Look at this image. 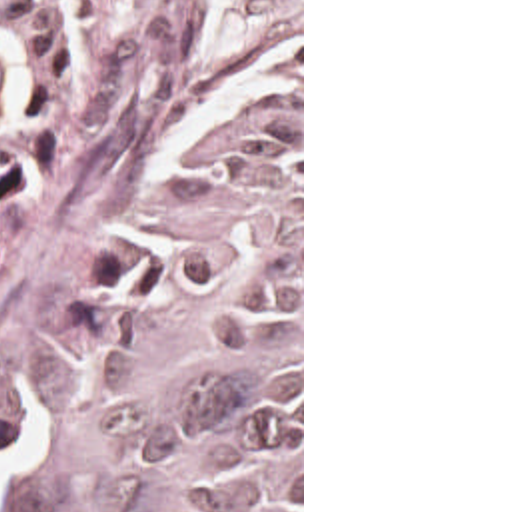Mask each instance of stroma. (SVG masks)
Here are the masks:
<instances>
[{"instance_id":"stroma-1","label":"stroma","mask_w":512,"mask_h":512,"mask_svg":"<svg viewBox=\"0 0 512 512\" xmlns=\"http://www.w3.org/2000/svg\"><path fill=\"white\" fill-rule=\"evenodd\" d=\"M300 72V512H304V0H98L64 98L0 188V512L46 395L136 236L210 186L222 110Z\"/></svg>"}]
</instances>
